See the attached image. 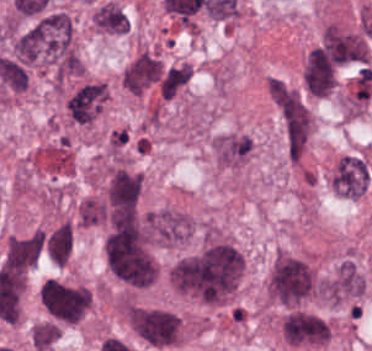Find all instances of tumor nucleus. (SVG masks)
Returning a JSON list of instances; mask_svg holds the SVG:
<instances>
[{"label":"tumor nucleus","instance_id":"feef74b5","mask_svg":"<svg viewBox=\"0 0 372 351\" xmlns=\"http://www.w3.org/2000/svg\"><path fill=\"white\" fill-rule=\"evenodd\" d=\"M147 235L151 242L178 244L191 236V220L173 209L147 213Z\"/></svg>","mask_w":372,"mask_h":351},{"label":"tumor nucleus","instance_id":"3d1891a8","mask_svg":"<svg viewBox=\"0 0 372 351\" xmlns=\"http://www.w3.org/2000/svg\"><path fill=\"white\" fill-rule=\"evenodd\" d=\"M278 331L286 344L297 347L324 344L330 335L329 326L324 319L313 312L299 309L285 313Z\"/></svg>","mask_w":372,"mask_h":351},{"label":"tumor nucleus","instance_id":"8087334f","mask_svg":"<svg viewBox=\"0 0 372 351\" xmlns=\"http://www.w3.org/2000/svg\"><path fill=\"white\" fill-rule=\"evenodd\" d=\"M368 180V163L357 155L340 157L329 174L331 188L349 199H358L366 190Z\"/></svg>","mask_w":372,"mask_h":351},{"label":"tumor nucleus","instance_id":"2cbd58db","mask_svg":"<svg viewBox=\"0 0 372 351\" xmlns=\"http://www.w3.org/2000/svg\"><path fill=\"white\" fill-rule=\"evenodd\" d=\"M309 287L306 263L284 251H277L266 278L267 294L291 303L304 296Z\"/></svg>","mask_w":372,"mask_h":351},{"label":"tumor nucleus","instance_id":"3e47fb67","mask_svg":"<svg viewBox=\"0 0 372 351\" xmlns=\"http://www.w3.org/2000/svg\"><path fill=\"white\" fill-rule=\"evenodd\" d=\"M107 101L104 82L86 81L66 98V114L73 122H92Z\"/></svg>","mask_w":372,"mask_h":351},{"label":"tumor nucleus","instance_id":"2f306a5c","mask_svg":"<svg viewBox=\"0 0 372 351\" xmlns=\"http://www.w3.org/2000/svg\"><path fill=\"white\" fill-rule=\"evenodd\" d=\"M244 259L229 242L211 241L167 269L177 292L208 303H224L236 290Z\"/></svg>","mask_w":372,"mask_h":351},{"label":"tumor nucleus","instance_id":"268c6acd","mask_svg":"<svg viewBox=\"0 0 372 351\" xmlns=\"http://www.w3.org/2000/svg\"><path fill=\"white\" fill-rule=\"evenodd\" d=\"M72 247L71 224L61 221L43 236V251L49 261L58 266L66 264Z\"/></svg>","mask_w":372,"mask_h":351},{"label":"tumor nucleus","instance_id":"3d7bf9ca","mask_svg":"<svg viewBox=\"0 0 372 351\" xmlns=\"http://www.w3.org/2000/svg\"><path fill=\"white\" fill-rule=\"evenodd\" d=\"M31 345L39 351L48 348L59 336V328L51 322L34 323L29 331Z\"/></svg>","mask_w":372,"mask_h":351},{"label":"tumor nucleus","instance_id":"5ab6c2c4","mask_svg":"<svg viewBox=\"0 0 372 351\" xmlns=\"http://www.w3.org/2000/svg\"><path fill=\"white\" fill-rule=\"evenodd\" d=\"M39 299L50 321L58 324L79 322L91 304V293L81 284L48 278Z\"/></svg>","mask_w":372,"mask_h":351},{"label":"tumor nucleus","instance_id":"8643909e","mask_svg":"<svg viewBox=\"0 0 372 351\" xmlns=\"http://www.w3.org/2000/svg\"><path fill=\"white\" fill-rule=\"evenodd\" d=\"M113 275L134 284L151 283L155 261L139 233L130 226H115L102 244Z\"/></svg>","mask_w":372,"mask_h":351},{"label":"tumor nucleus","instance_id":"2083b535","mask_svg":"<svg viewBox=\"0 0 372 351\" xmlns=\"http://www.w3.org/2000/svg\"><path fill=\"white\" fill-rule=\"evenodd\" d=\"M138 337L155 347H168L178 338L175 314L158 308L139 307Z\"/></svg>","mask_w":372,"mask_h":351},{"label":"tumor nucleus","instance_id":"962dda3e","mask_svg":"<svg viewBox=\"0 0 372 351\" xmlns=\"http://www.w3.org/2000/svg\"><path fill=\"white\" fill-rule=\"evenodd\" d=\"M191 78V66L178 62L163 68L158 93L161 99H171Z\"/></svg>","mask_w":372,"mask_h":351},{"label":"tumor nucleus","instance_id":"1edb0cf7","mask_svg":"<svg viewBox=\"0 0 372 351\" xmlns=\"http://www.w3.org/2000/svg\"><path fill=\"white\" fill-rule=\"evenodd\" d=\"M90 25L102 34H125L128 31L127 15L113 1H106L94 8Z\"/></svg>","mask_w":372,"mask_h":351},{"label":"tumor nucleus","instance_id":"f7901128","mask_svg":"<svg viewBox=\"0 0 372 351\" xmlns=\"http://www.w3.org/2000/svg\"><path fill=\"white\" fill-rule=\"evenodd\" d=\"M161 74V66L149 52L142 51L122 71L124 88L133 94H141L152 85Z\"/></svg>","mask_w":372,"mask_h":351},{"label":"tumor nucleus","instance_id":"c2bd9aea","mask_svg":"<svg viewBox=\"0 0 372 351\" xmlns=\"http://www.w3.org/2000/svg\"><path fill=\"white\" fill-rule=\"evenodd\" d=\"M366 282L362 271L350 261H343L322 282L326 301L340 303L362 296Z\"/></svg>","mask_w":372,"mask_h":351},{"label":"tumor nucleus","instance_id":"80c4ae96","mask_svg":"<svg viewBox=\"0 0 372 351\" xmlns=\"http://www.w3.org/2000/svg\"><path fill=\"white\" fill-rule=\"evenodd\" d=\"M106 218V204L101 198L92 196L79 203L78 223L80 226L88 227L103 223Z\"/></svg>","mask_w":372,"mask_h":351}]
</instances>
